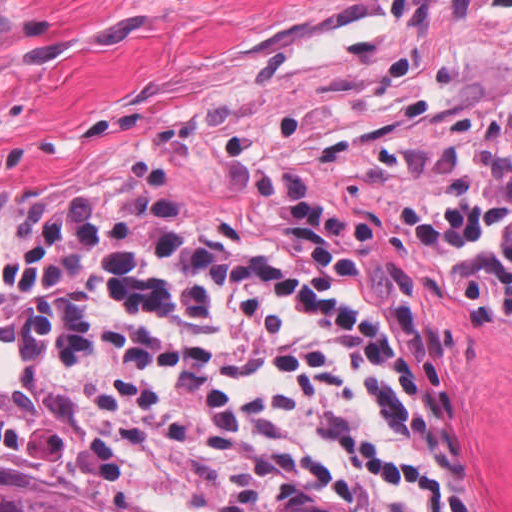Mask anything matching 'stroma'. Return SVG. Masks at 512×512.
<instances>
[{"instance_id": "obj_1", "label": "stroma", "mask_w": 512, "mask_h": 512, "mask_svg": "<svg viewBox=\"0 0 512 512\" xmlns=\"http://www.w3.org/2000/svg\"><path fill=\"white\" fill-rule=\"evenodd\" d=\"M511 81L512 0H418L50 213L100 203L158 239L279 260L303 199H348L444 372L454 477L478 512H512V341L446 312L395 201L410 141ZM29 225L0 241V388L27 384L31 367V340L3 301V251ZM0 479L121 491L158 512H227L140 473L14 453H0Z\"/></svg>"}]
</instances>
